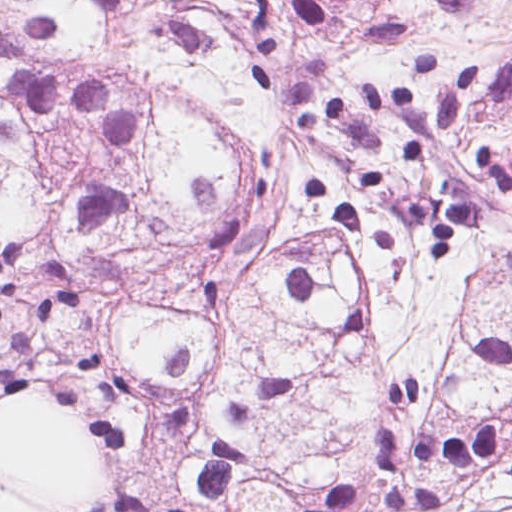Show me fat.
<instances>
[{"label":"fat","mask_w":512,"mask_h":512,"mask_svg":"<svg viewBox=\"0 0 512 512\" xmlns=\"http://www.w3.org/2000/svg\"><path fill=\"white\" fill-rule=\"evenodd\" d=\"M0 512H88L103 496L106 464L79 422L25 405L0 416Z\"/></svg>","instance_id":"1"}]
</instances>
